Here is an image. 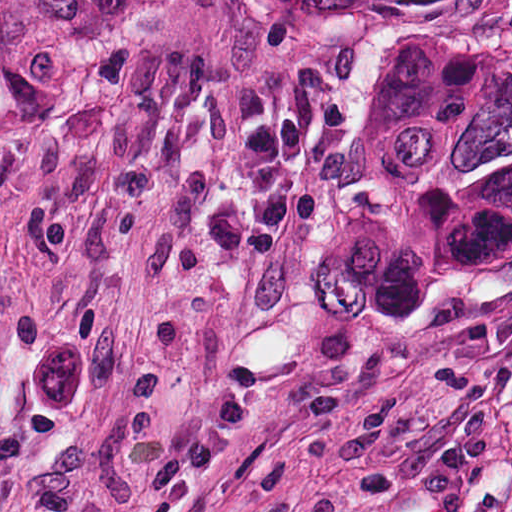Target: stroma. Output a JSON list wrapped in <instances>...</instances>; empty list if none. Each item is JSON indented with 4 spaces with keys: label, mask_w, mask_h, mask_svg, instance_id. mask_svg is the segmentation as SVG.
Segmentation results:
<instances>
[{
    "label": "stroma",
    "mask_w": 512,
    "mask_h": 512,
    "mask_svg": "<svg viewBox=\"0 0 512 512\" xmlns=\"http://www.w3.org/2000/svg\"><path fill=\"white\" fill-rule=\"evenodd\" d=\"M397 2L24 0L0 76V512H512V258L416 322L315 280ZM297 118L273 256L237 164Z\"/></svg>",
    "instance_id": "35a3bbf8"
}]
</instances>
